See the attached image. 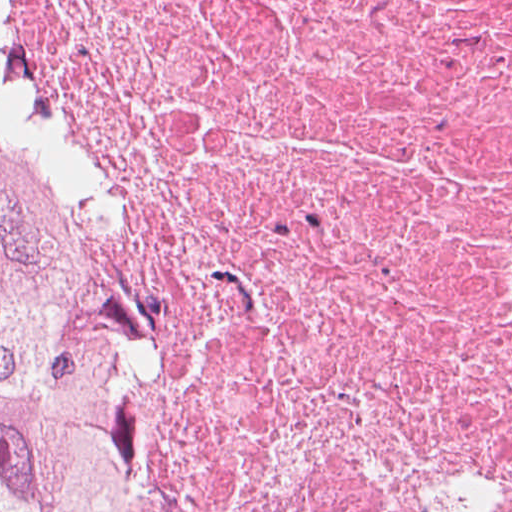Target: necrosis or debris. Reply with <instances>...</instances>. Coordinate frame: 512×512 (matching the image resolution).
Returning a JSON list of instances; mask_svg holds the SVG:
<instances>
[{"label":"necrosis or debris","mask_w":512,"mask_h":512,"mask_svg":"<svg viewBox=\"0 0 512 512\" xmlns=\"http://www.w3.org/2000/svg\"><path fill=\"white\" fill-rule=\"evenodd\" d=\"M125 512H512V0H0Z\"/></svg>","instance_id":"4bbe7bcc"}]
</instances>
